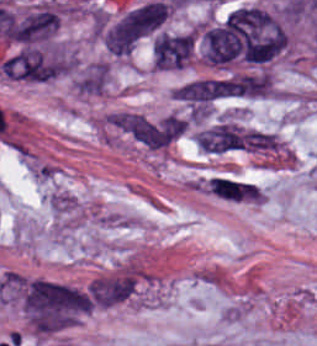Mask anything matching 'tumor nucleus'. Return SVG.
<instances>
[{"label": "tumor nucleus", "mask_w": 317, "mask_h": 346, "mask_svg": "<svg viewBox=\"0 0 317 346\" xmlns=\"http://www.w3.org/2000/svg\"><path fill=\"white\" fill-rule=\"evenodd\" d=\"M166 8L157 0L146 1L123 14L103 34L106 48L131 49L164 19Z\"/></svg>", "instance_id": "tumor-nucleus-1"}, {"label": "tumor nucleus", "mask_w": 317, "mask_h": 346, "mask_svg": "<svg viewBox=\"0 0 317 346\" xmlns=\"http://www.w3.org/2000/svg\"><path fill=\"white\" fill-rule=\"evenodd\" d=\"M191 49L190 34H160L152 43L153 63L159 69H180Z\"/></svg>", "instance_id": "tumor-nucleus-2"}]
</instances>
